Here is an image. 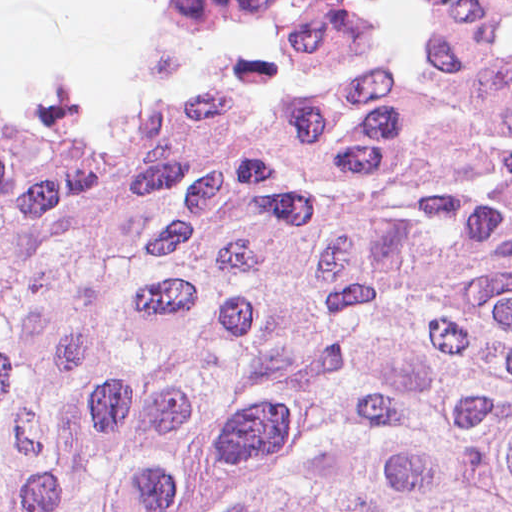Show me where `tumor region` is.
Here are the masks:
<instances>
[{
	"mask_svg": "<svg viewBox=\"0 0 512 512\" xmlns=\"http://www.w3.org/2000/svg\"><path fill=\"white\" fill-rule=\"evenodd\" d=\"M0 512H512V0L0 119Z\"/></svg>",
	"mask_w": 512,
	"mask_h": 512,
	"instance_id": "obj_1",
	"label": "tumor region"
}]
</instances>
